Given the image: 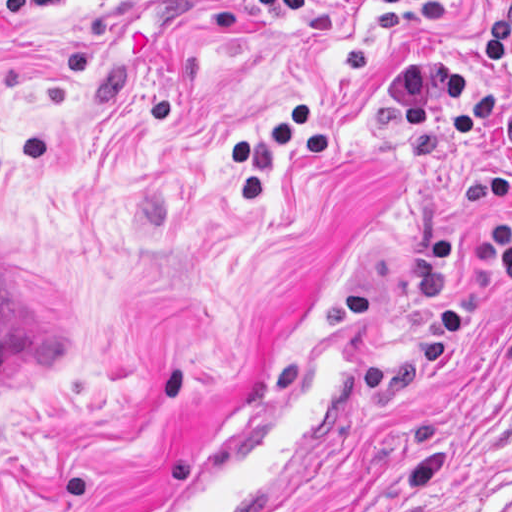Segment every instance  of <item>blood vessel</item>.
Wrapping results in <instances>:
<instances>
[{
	"label": "blood vessel",
	"mask_w": 512,
	"mask_h": 512,
	"mask_svg": "<svg viewBox=\"0 0 512 512\" xmlns=\"http://www.w3.org/2000/svg\"><path fill=\"white\" fill-rule=\"evenodd\" d=\"M350 286L208 447L135 512H309L344 477L374 420V350Z\"/></svg>",
	"instance_id": "blood-vessel-1"
}]
</instances>
